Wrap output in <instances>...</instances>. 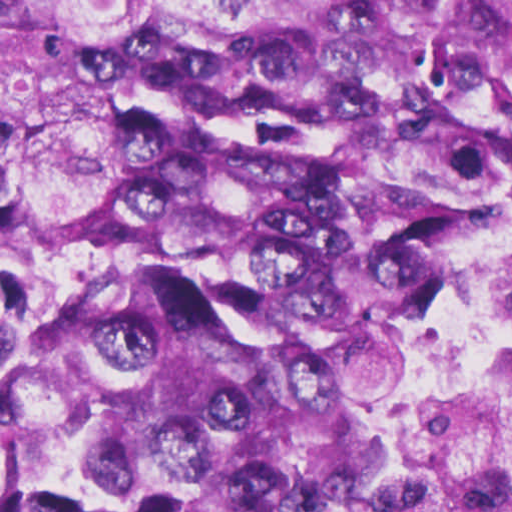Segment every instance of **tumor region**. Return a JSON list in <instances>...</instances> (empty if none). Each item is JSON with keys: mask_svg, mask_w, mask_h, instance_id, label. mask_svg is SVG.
Wrapping results in <instances>:
<instances>
[{"mask_svg": "<svg viewBox=\"0 0 512 512\" xmlns=\"http://www.w3.org/2000/svg\"><path fill=\"white\" fill-rule=\"evenodd\" d=\"M510 157L512 0H0V512H382Z\"/></svg>", "mask_w": 512, "mask_h": 512, "instance_id": "obj_1", "label": "tumor region"}]
</instances>
